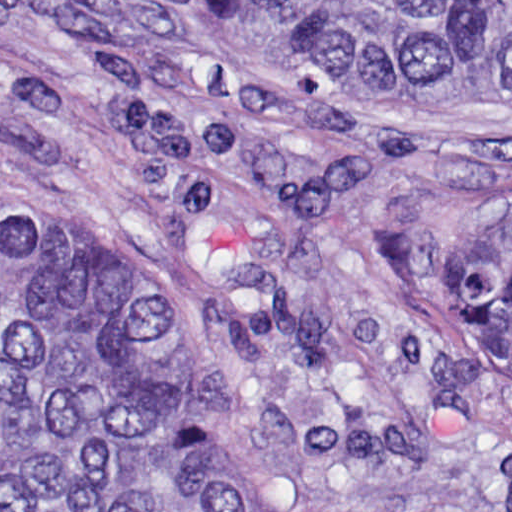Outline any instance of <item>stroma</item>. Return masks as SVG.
Segmentation results:
<instances>
[{"instance_id": "obj_1", "label": "stroma", "mask_w": 512, "mask_h": 512, "mask_svg": "<svg viewBox=\"0 0 512 512\" xmlns=\"http://www.w3.org/2000/svg\"><path fill=\"white\" fill-rule=\"evenodd\" d=\"M507 220L512 114L378 107L213 0H0V223L143 289L267 512H512Z\"/></svg>"}]
</instances>
